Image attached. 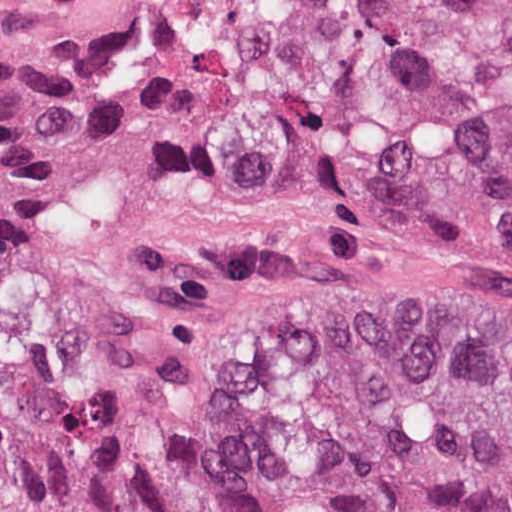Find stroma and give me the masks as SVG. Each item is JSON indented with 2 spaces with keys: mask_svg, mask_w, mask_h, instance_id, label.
Segmentation results:
<instances>
[{
  "mask_svg": "<svg viewBox=\"0 0 512 512\" xmlns=\"http://www.w3.org/2000/svg\"><path fill=\"white\" fill-rule=\"evenodd\" d=\"M190 0H0V152L40 179L0 274L16 363L85 400L234 434L228 321L303 292L512 304V248L373 219L183 149Z\"/></svg>",
  "mask_w": 512,
  "mask_h": 512,
  "instance_id": "1",
  "label": "stroma"
}]
</instances>
